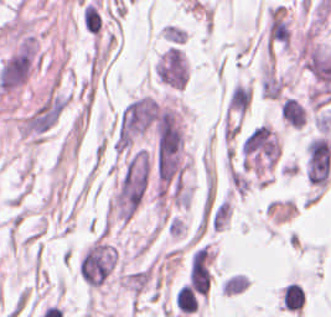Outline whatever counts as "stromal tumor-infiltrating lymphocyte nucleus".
<instances>
[{
  "label": "stromal tumor-infiltrating lymphocyte nucleus",
  "mask_w": 331,
  "mask_h": 317,
  "mask_svg": "<svg viewBox=\"0 0 331 317\" xmlns=\"http://www.w3.org/2000/svg\"><path fill=\"white\" fill-rule=\"evenodd\" d=\"M198 299L187 284H182L176 292V307L182 311H195Z\"/></svg>",
  "instance_id": "1"
}]
</instances>
